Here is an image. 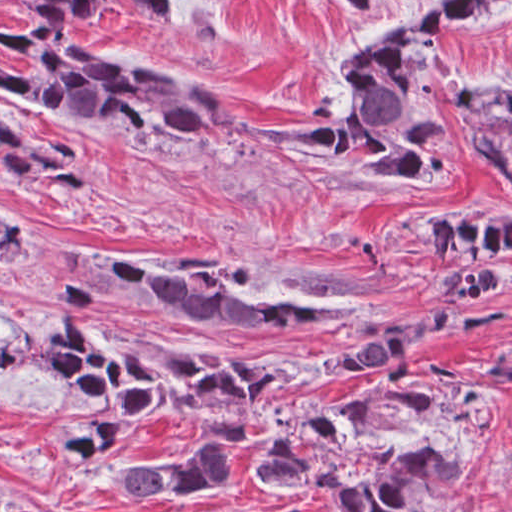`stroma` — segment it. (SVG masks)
I'll list each match as a JSON object with an SVG mask.
<instances>
[{
	"instance_id": "1",
	"label": "stroma",
	"mask_w": 512,
	"mask_h": 512,
	"mask_svg": "<svg viewBox=\"0 0 512 512\" xmlns=\"http://www.w3.org/2000/svg\"><path fill=\"white\" fill-rule=\"evenodd\" d=\"M431 0H380L350 14L337 0H180L162 25L130 0H109L112 15L80 23L98 63L192 71L236 96L255 125L306 128L312 99L334 68L368 39L404 26ZM1 18L32 23L20 4L0 0V512H346L335 492L264 479L258 465L292 411L363 390L379 373L356 371L279 395L235 442L190 418L133 422L112 451L88 466L62 462L82 425V403L61 376H46L42 349L68 323L90 320L119 339L175 351L276 361L283 367L357 355L366 342L318 331L269 327L196 332L146 324L58 296L55 282L89 275L98 256L171 265L194 263L235 287L290 293L370 322L425 323L450 311L442 265L429 239L444 220H512V180L478 158L468 136L443 123L453 158L438 180L348 181L309 153L280 144L246 147L235 138L199 154L148 140L121 125L72 121L1 85V64L22 53L1 42ZM426 54L434 82L477 90L512 86V0L484 18L432 34ZM1 115L28 134L87 153L89 192L35 190L1 171ZM1 214L19 223V256L1 269ZM506 307L492 332L463 344L434 334L409 371L440 400L406 431L380 445L444 448L471 463L458 480L453 512H512V386L484 366L512 341V280L484 300ZM223 443L230 472L199 500L141 505L126 497L123 466L178 458Z\"/></svg>"
}]
</instances>
